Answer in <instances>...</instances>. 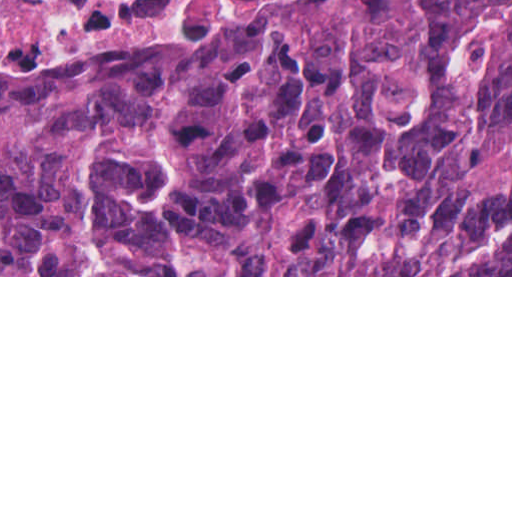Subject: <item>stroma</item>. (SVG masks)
I'll return each instance as SVG.
<instances>
[{
  "label": "stroma",
  "instance_id": "35a3bbf8",
  "mask_svg": "<svg viewBox=\"0 0 512 512\" xmlns=\"http://www.w3.org/2000/svg\"><path fill=\"white\" fill-rule=\"evenodd\" d=\"M380 0H177L128 25L15 22L0 67L91 53L132 57L360 13ZM0 277H512V275H0Z\"/></svg>",
  "mask_w": 512,
  "mask_h": 512
}]
</instances>
